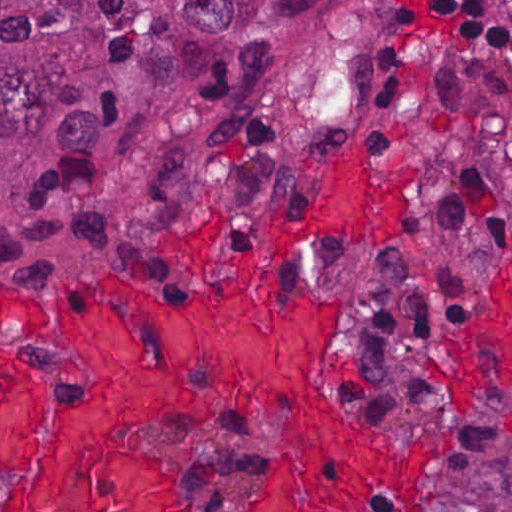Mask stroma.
<instances>
[{
	"mask_svg": "<svg viewBox=\"0 0 512 512\" xmlns=\"http://www.w3.org/2000/svg\"><path fill=\"white\" fill-rule=\"evenodd\" d=\"M415 1L417 0H387L383 17L372 37V101L378 111L380 110L377 104V65L383 38L400 9ZM360 140H363L375 165L383 169L399 168L414 160L420 167L410 185V197L400 232L383 249L366 253L357 248L350 233L335 220L325 226L320 237H306L298 241L284 256L276 276V289L278 296L287 299L300 286L313 288L322 297L339 302L341 332L325 349V369L336 399L333 408L359 421L372 424L380 433L399 439L452 438L448 447L439 455L438 461L443 453L453 449L456 434L464 419L475 413L476 408L471 400L473 391L487 384L498 383L501 388L512 392V263L501 257L486 227L477 199L470 213V242L481 268V311L475 321L450 329L443 350L418 366V374L436 403L437 424L434 426H382L349 408L340 395V381L345 375L343 348L351 321V305L346 293L335 284L312 279L296 280L286 291L279 284L283 272L295 257L312 252L321 246H334L352 257L383 256L399 249L406 240L418 209L424 158L413 152L380 155L374 151L367 136L362 132H350L330 146L327 157L322 161L303 202L281 204L260 215L247 235L241 264L234 273L223 277L206 274L200 280H154L103 272L84 280L70 295L50 291L40 277L24 264L1 260L0 0V512L2 498L28 483L44 469L61 412L82 405L86 399L84 378L80 370L72 364L68 354L42 343H29L21 339L17 329L1 310V286L17 297L47 308L64 301L77 291L115 280L129 287L148 291L152 297L173 305L178 315H189L194 306V295L200 287L216 279L243 278L259 224L278 217L291 224H308L314 220L321 203V179L325 169L353 142ZM210 273L225 272L212 269ZM328 411L330 405L321 392L313 405L305 411L296 413L294 419L311 420ZM238 416L279 418V432L275 436L272 456L266 468L264 490L255 498L253 505V512H256L258 504L274 496L280 487L282 467L288 453L290 418L264 406L222 409L216 413L193 415L167 426L149 427L139 432L145 447L161 451L176 463L178 512L190 511L181 483L180 458L174 446L159 445L151 441L148 435L174 433ZM507 426L512 432V410L507 416ZM436 463L426 479L428 512H433L430 503V475Z\"/></svg>",
	"mask_w": 512,
	"mask_h": 512,
	"instance_id": "stroma-1",
	"label": "stroma"
}]
</instances>
